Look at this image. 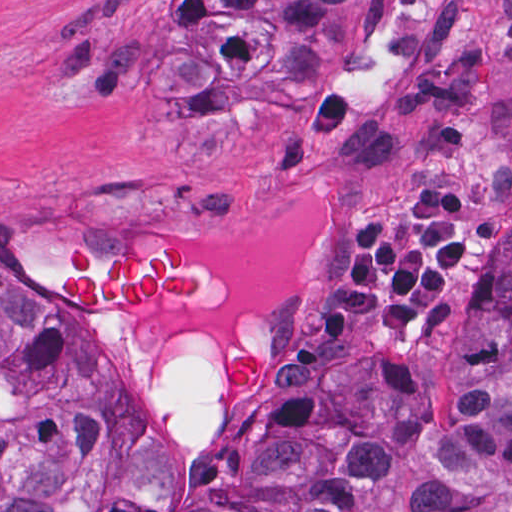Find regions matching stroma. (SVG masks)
<instances>
[{
    "label": "stroma",
    "instance_id": "1",
    "mask_svg": "<svg viewBox=\"0 0 512 512\" xmlns=\"http://www.w3.org/2000/svg\"><path fill=\"white\" fill-rule=\"evenodd\" d=\"M89 1H379V19L325 70L309 156L285 175L281 143L242 122L203 155L143 94H76L48 71V38ZM454 165H480L486 222L455 279V329L405 346L355 321L317 352H290L291 303L331 266L348 206L372 214ZM185 232L206 275V305L176 320L100 317L54 295L45 250L57 239L114 253L165 226ZM512 239V0H0V276L62 314L100 352L156 430V478L141 498L175 512L214 435L251 404L318 387L337 357L370 353L386 380L436 381L468 326L478 278ZM215 344L211 430L167 435L162 374L182 326ZM245 336L267 376L218 385L225 342Z\"/></svg>",
    "mask_w": 512,
    "mask_h": 512
}]
</instances>
